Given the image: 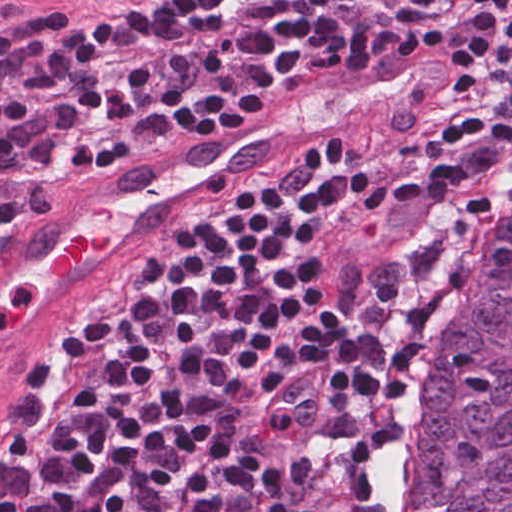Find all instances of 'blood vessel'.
Returning <instances> with one entry per match:
<instances>
[{
  "label": "blood vessel",
  "instance_id": "obj_1",
  "mask_svg": "<svg viewBox=\"0 0 512 512\" xmlns=\"http://www.w3.org/2000/svg\"><path fill=\"white\" fill-rule=\"evenodd\" d=\"M471 45L423 20L342 63L206 151L60 204L0 257V376L117 240L210 176L399 119L443 89Z\"/></svg>",
  "mask_w": 512,
  "mask_h": 512
}]
</instances>
